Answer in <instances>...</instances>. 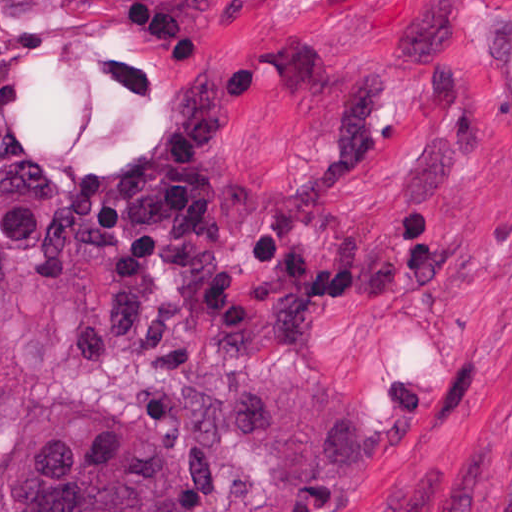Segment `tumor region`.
Wrapping results in <instances>:
<instances>
[{
	"mask_svg": "<svg viewBox=\"0 0 512 512\" xmlns=\"http://www.w3.org/2000/svg\"><path fill=\"white\" fill-rule=\"evenodd\" d=\"M143 312L135 226L74 212L36 161H0V512H185L156 439L39 395Z\"/></svg>",
	"mask_w": 512,
	"mask_h": 512,
	"instance_id": "obj_1",
	"label": "tumor region"
}]
</instances>
